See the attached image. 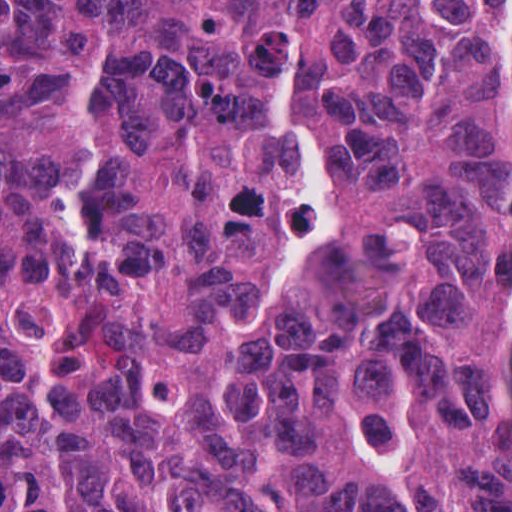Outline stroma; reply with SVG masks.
Listing matches in <instances>:
<instances>
[{"label": "stroma", "instance_id": "35a3bbf8", "mask_svg": "<svg viewBox=\"0 0 512 512\" xmlns=\"http://www.w3.org/2000/svg\"><path fill=\"white\" fill-rule=\"evenodd\" d=\"M0 1H512V0H0ZM497 332L512 376V292L497 295Z\"/></svg>", "mask_w": 512, "mask_h": 512}]
</instances>
